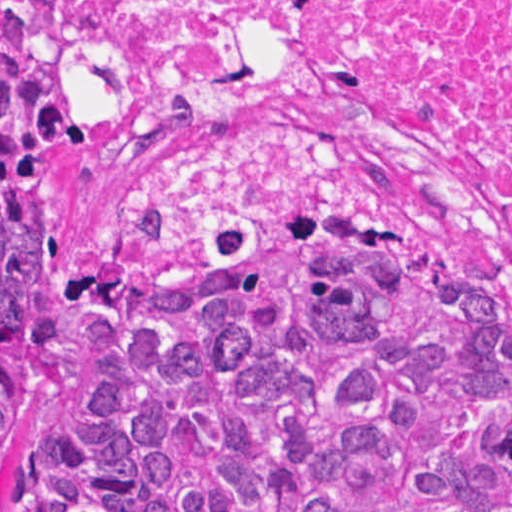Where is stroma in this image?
<instances>
[{
  "label": "stroma",
  "instance_id": "stroma-1",
  "mask_svg": "<svg viewBox=\"0 0 512 512\" xmlns=\"http://www.w3.org/2000/svg\"><path fill=\"white\" fill-rule=\"evenodd\" d=\"M68 51L79 78L77 0ZM40 177L75 272L72 290L109 257L146 261L90 148L51 160ZM397 235L438 257L512 310V278L501 276L460 246L445 220ZM95 375V338L69 307L0 410V512H13L9 479L17 453L29 446L52 413L80 399Z\"/></svg>",
  "mask_w": 512,
  "mask_h": 512
}]
</instances>
